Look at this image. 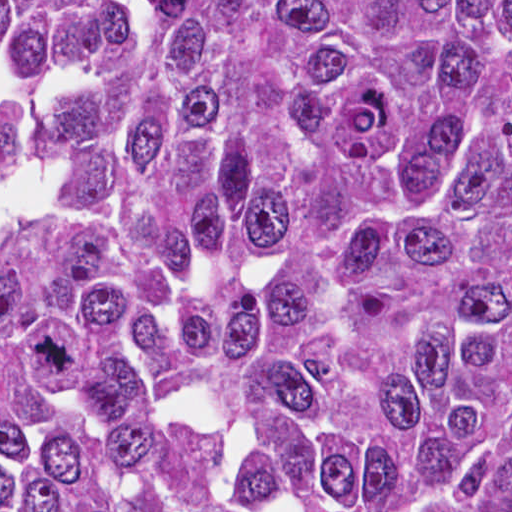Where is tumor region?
<instances>
[{"label": "tumor region", "mask_w": 512, "mask_h": 512, "mask_svg": "<svg viewBox=\"0 0 512 512\" xmlns=\"http://www.w3.org/2000/svg\"><path fill=\"white\" fill-rule=\"evenodd\" d=\"M0 512H512V1H0Z\"/></svg>", "instance_id": "1"}]
</instances>
